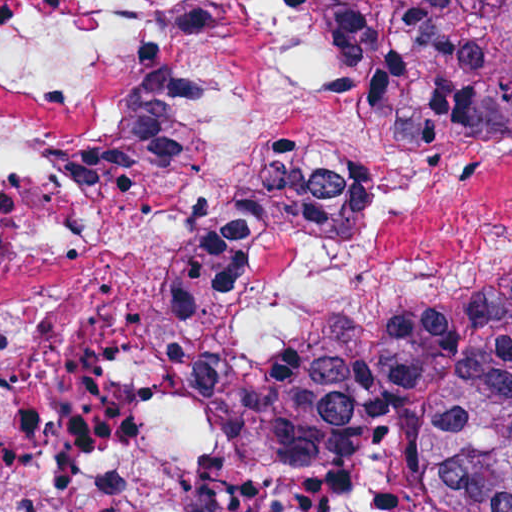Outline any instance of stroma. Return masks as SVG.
Instances as JSON below:
<instances>
[{
  "label": "stroma",
  "instance_id": "1",
  "mask_svg": "<svg viewBox=\"0 0 512 512\" xmlns=\"http://www.w3.org/2000/svg\"><path fill=\"white\" fill-rule=\"evenodd\" d=\"M0 1H512V0H0ZM395 37V36H389ZM405 146H464V145H405ZM512 279V271L498 277L486 284H483L470 292H468L463 297L472 296L482 289L496 283L504 282ZM458 299V300H459ZM377 318H347L337 324L316 328L308 331L301 332L292 337H289L278 344L260 352V353H284L288 351H292L297 348L299 345L304 343L305 341L318 336L324 332L339 328L344 325L360 323L364 321H369ZM230 355V354H228ZM227 357V355H222V357L214 358L203 365H201L198 369L195 370L191 384H190V402L194 412V416L198 421V386L199 381L204 373V371L209 368L214 363L219 360ZM219 446V445H218ZM220 448V446H219ZM221 449V448H220ZM232 464V463H231ZM234 468L241 471L245 475L267 485L279 486V485H287L293 483L295 480L303 476L301 473L288 472L276 468H271L267 466H239L232 464ZM418 469V445L416 444V471Z\"/></svg>",
  "mask_w": 512,
  "mask_h": 512
}]
</instances>
